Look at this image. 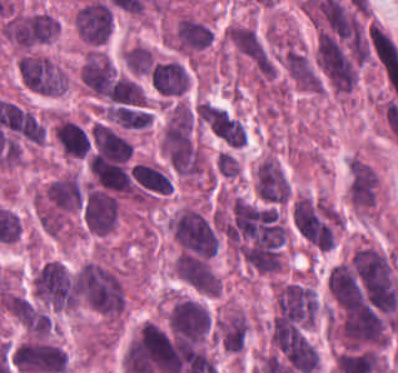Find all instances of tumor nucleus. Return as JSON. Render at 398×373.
Returning a JSON list of instances; mask_svg holds the SVG:
<instances>
[{
    "label": "tumor nucleus",
    "instance_id": "11",
    "mask_svg": "<svg viewBox=\"0 0 398 373\" xmlns=\"http://www.w3.org/2000/svg\"><path fill=\"white\" fill-rule=\"evenodd\" d=\"M280 62L287 77L300 89L318 92L320 75L313 58L295 42L285 43Z\"/></svg>",
    "mask_w": 398,
    "mask_h": 373
},
{
    "label": "tumor nucleus",
    "instance_id": "21",
    "mask_svg": "<svg viewBox=\"0 0 398 373\" xmlns=\"http://www.w3.org/2000/svg\"><path fill=\"white\" fill-rule=\"evenodd\" d=\"M216 167L224 175H233L238 171V162L232 155L220 150L216 154Z\"/></svg>",
    "mask_w": 398,
    "mask_h": 373
},
{
    "label": "tumor nucleus",
    "instance_id": "9",
    "mask_svg": "<svg viewBox=\"0 0 398 373\" xmlns=\"http://www.w3.org/2000/svg\"><path fill=\"white\" fill-rule=\"evenodd\" d=\"M214 37L208 22L183 12L169 29L167 41L176 51L191 56L211 45Z\"/></svg>",
    "mask_w": 398,
    "mask_h": 373
},
{
    "label": "tumor nucleus",
    "instance_id": "5",
    "mask_svg": "<svg viewBox=\"0 0 398 373\" xmlns=\"http://www.w3.org/2000/svg\"><path fill=\"white\" fill-rule=\"evenodd\" d=\"M171 230L185 250L207 258L217 250L216 236L200 210L183 205L171 218Z\"/></svg>",
    "mask_w": 398,
    "mask_h": 373
},
{
    "label": "tumor nucleus",
    "instance_id": "16",
    "mask_svg": "<svg viewBox=\"0 0 398 373\" xmlns=\"http://www.w3.org/2000/svg\"><path fill=\"white\" fill-rule=\"evenodd\" d=\"M150 80L158 94L171 97L188 89L189 73L179 60H160L151 66Z\"/></svg>",
    "mask_w": 398,
    "mask_h": 373
},
{
    "label": "tumor nucleus",
    "instance_id": "20",
    "mask_svg": "<svg viewBox=\"0 0 398 373\" xmlns=\"http://www.w3.org/2000/svg\"><path fill=\"white\" fill-rule=\"evenodd\" d=\"M254 188L259 200L266 204H286L260 161L255 169Z\"/></svg>",
    "mask_w": 398,
    "mask_h": 373
},
{
    "label": "tumor nucleus",
    "instance_id": "3",
    "mask_svg": "<svg viewBox=\"0 0 398 373\" xmlns=\"http://www.w3.org/2000/svg\"><path fill=\"white\" fill-rule=\"evenodd\" d=\"M1 31L10 44L28 50L58 35L55 17L38 10H18L6 15Z\"/></svg>",
    "mask_w": 398,
    "mask_h": 373
},
{
    "label": "tumor nucleus",
    "instance_id": "13",
    "mask_svg": "<svg viewBox=\"0 0 398 373\" xmlns=\"http://www.w3.org/2000/svg\"><path fill=\"white\" fill-rule=\"evenodd\" d=\"M52 133L63 154L87 157L91 151V131L69 116L56 115Z\"/></svg>",
    "mask_w": 398,
    "mask_h": 373
},
{
    "label": "tumor nucleus",
    "instance_id": "6",
    "mask_svg": "<svg viewBox=\"0 0 398 373\" xmlns=\"http://www.w3.org/2000/svg\"><path fill=\"white\" fill-rule=\"evenodd\" d=\"M37 295L54 309L77 305V291L65 266L57 260L46 262L33 274Z\"/></svg>",
    "mask_w": 398,
    "mask_h": 373
},
{
    "label": "tumor nucleus",
    "instance_id": "17",
    "mask_svg": "<svg viewBox=\"0 0 398 373\" xmlns=\"http://www.w3.org/2000/svg\"><path fill=\"white\" fill-rule=\"evenodd\" d=\"M222 347L240 350L245 340L247 316L241 308H231L215 322Z\"/></svg>",
    "mask_w": 398,
    "mask_h": 373
},
{
    "label": "tumor nucleus",
    "instance_id": "1",
    "mask_svg": "<svg viewBox=\"0 0 398 373\" xmlns=\"http://www.w3.org/2000/svg\"><path fill=\"white\" fill-rule=\"evenodd\" d=\"M73 286L82 304L119 318L126 306V288L115 268L101 260L87 259L73 270Z\"/></svg>",
    "mask_w": 398,
    "mask_h": 373
},
{
    "label": "tumor nucleus",
    "instance_id": "7",
    "mask_svg": "<svg viewBox=\"0 0 398 373\" xmlns=\"http://www.w3.org/2000/svg\"><path fill=\"white\" fill-rule=\"evenodd\" d=\"M225 41L259 76L268 77L271 58L255 27L248 24L230 22L224 31Z\"/></svg>",
    "mask_w": 398,
    "mask_h": 373
},
{
    "label": "tumor nucleus",
    "instance_id": "14",
    "mask_svg": "<svg viewBox=\"0 0 398 373\" xmlns=\"http://www.w3.org/2000/svg\"><path fill=\"white\" fill-rule=\"evenodd\" d=\"M73 19L77 32L86 41L104 42L111 31V7L98 1L87 2Z\"/></svg>",
    "mask_w": 398,
    "mask_h": 373
},
{
    "label": "tumor nucleus",
    "instance_id": "2",
    "mask_svg": "<svg viewBox=\"0 0 398 373\" xmlns=\"http://www.w3.org/2000/svg\"><path fill=\"white\" fill-rule=\"evenodd\" d=\"M318 309L316 294L300 280L286 279L274 290L272 325L308 328Z\"/></svg>",
    "mask_w": 398,
    "mask_h": 373
},
{
    "label": "tumor nucleus",
    "instance_id": "12",
    "mask_svg": "<svg viewBox=\"0 0 398 373\" xmlns=\"http://www.w3.org/2000/svg\"><path fill=\"white\" fill-rule=\"evenodd\" d=\"M205 125L226 145L240 146L246 137V129L237 114L212 102L202 105Z\"/></svg>",
    "mask_w": 398,
    "mask_h": 373
},
{
    "label": "tumor nucleus",
    "instance_id": "10",
    "mask_svg": "<svg viewBox=\"0 0 398 373\" xmlns=\"http://www.w3.org/2000/svg\"><path fill=\"white\" fill-rule=\"evenodd\" d=\"M167 321L178 337L202 339L210 325V312L191 298H177L172 304Z\"/></svg>",
    "mask_w": 398,
    "mask_h": 373
},
{
    "label": "tumor nucleus",
    "instance_id": "4",
    "mask_svg": "<svg viewBox=\"0 0 398 373\" xmlns=\"http://www.w3.org/2000/svg\"><path fill=\"white\" fill-rule=\"evenodd\" d=\"M17 67L23 85L39 94H59L68 86L65 69L38 51H24Z\"/></svg>",
    "mask_w": 398,
    "mask_h": 373
},
{
    "label": "tumor nucleus",
    "instance_id": "18",
    "mask_svg": "<svg viewBox=\"0 0 398 373\" xmlns=\"http://www.w3.org/2000/svg\"><path fill=\"white\" fill-rule=\"evenodd\" d=\"M193 126L191 108L184 101H177L171 105L165 121L162 138L163 141L176 143L187 137Z\"/></svg>",
    "mask_w": 398,
    "mask_h": 373
},
{
    "label": "tumor nucleus",
    "instance_id": "8",
    "mask_svg": "<svg viewBox=\"0 0 398 373\" xmlns=\"http://www.w3.org/2000/svg\"><path fill=\"white\" fill-rule=\"evenodd\" d=\"M173 271L193 290L206 295L220 293L221 280L210 258L205 255L181 249L173 260Z\"/></svg>",
    "mask_w": 398,
    "mask_h": 373
},
{
    "label": "tumor nucleus",
    "instance_id": "15",
    "mask_svg": "<svg viewBox=\"0 0 398 373\" xmlns=\"http://www.w3.org/2000/svg\"><path fill=\"white\" fill-rule=\"evenodd\" d=\"M346 192L353 208L370 211L379 192V174L371 166H351Z\"/></svg>",
    "mask_w": 398,
    "mask_h": 373
},
{
    "label": "tumor nucleus",
    "instance_id": "19",
    "mask_svg": "<svg viewBox=\"0 0 398 373\" xmlns=\"http://www.w3.org/2000/svg\"><path fill=\"white\" fill-rule=\"evenodd\" d=\"M121 58L130 73L148 75L152 65L153 52L143 43L133 42L122 50Z\"/></svg>",
    "mask_w": 398,
    "mask_h": 373
}]
</instances>
